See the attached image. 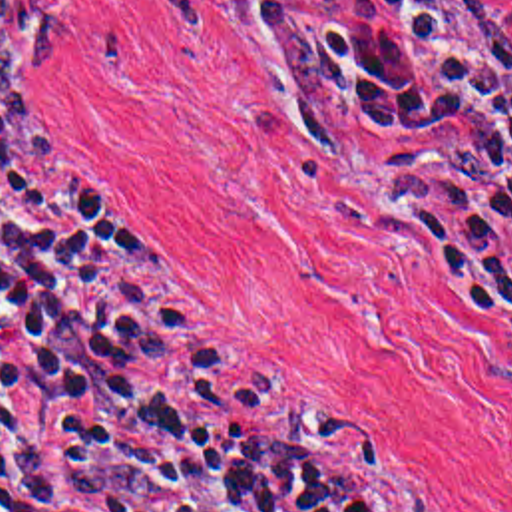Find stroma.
Here are the masks:
<instances>
[{"label":"stroma","mask_w":512,"mask_h":512,"mask_svg":"<svg viewBox=\"0 0 512 512\" xmlns=\"http://www.w3.org/2000/svg\"><path fill=\"white\" fill-rule=\"evenodd\" d=\"M45 1L53 51L0 131L145 250L175 340L298 392L422 511L512 512V342L408 208L442 151L316 153L254 0ZM458 1L512 95V0Z\"/></svg>","instance_id":"1"}]
</instances>
